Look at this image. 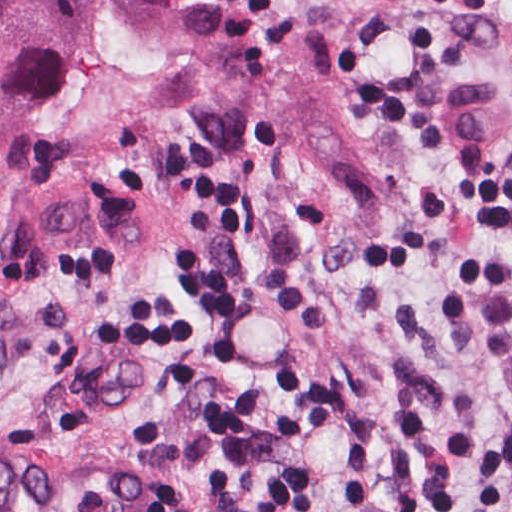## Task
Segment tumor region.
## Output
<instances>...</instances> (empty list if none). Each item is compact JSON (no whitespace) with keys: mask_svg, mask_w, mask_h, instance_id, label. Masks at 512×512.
<instances>
[{"mask_svg":"<svg viewBox=\"0 0 512 512\" xmlns=\"http://www.w3.org/2000/svg\"><path fill=\"white\" fill-rule=\"evenodd\" d=\"M198 1L0 0V153L29 115L95 108L137 85ZM399 2L217 0L186 41L189 72L216 107L359 180L368 66ZM0 268L29 275L10 221Z\"/></svg>","mask_w":512,"mask_h":512,"instance_id":"e687c5a6","label":"tumor region"}]
</instances>
